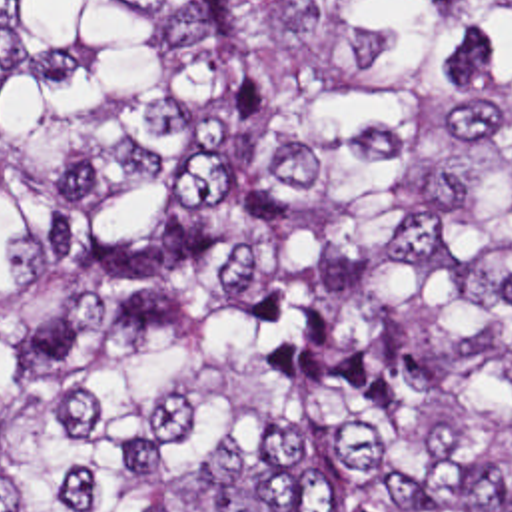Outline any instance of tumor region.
<instances>
[{
  "label": "tumor region",
  "mask_w": 512,
  "mask_h": 512,
  "mask_svg": "<svg viewBox=\"0 0 512 512\" xmlns=\"http://www.w3.org/2000/svg\"><path fill=\"white\" fill-rule=\"evenodd\" d=\"M0 512H512V0H0Z\"/></svg>",
  "instance_id": "tumor-region-1"
}]
</instances>
